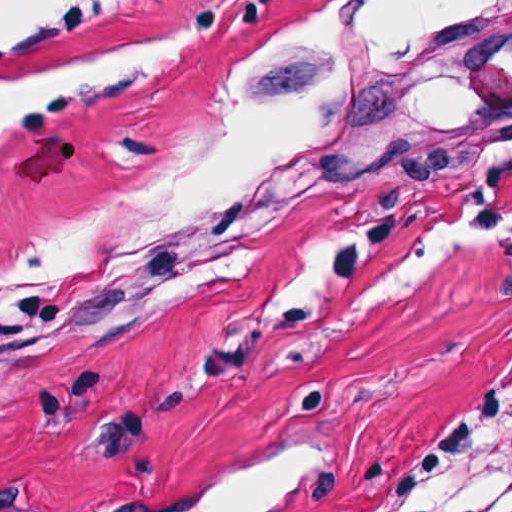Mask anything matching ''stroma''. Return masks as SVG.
I'll use <instances>...</instances> for the list:
<instances>
[{
  "instance_id": "1",
  "label": "stroma",
  "mask_w": 512,
  "mask_h": 512,
  "mask_svg": "<svg viewBox=\"0 0 512 512\" xmlns=\"http://www.w3.org/2000/svg\"><path fill=\"white\" fill-rule=\"evenodd\" d=\"M309 1L61 0L2 40L6 83L210 33L134 92L0 140V249L196 118ZM510 427L512 23L477 123L357 163L277 244L214 220L174 309L0 341V512H141L276 454L286 512H404Z\"/></svg>"
}]
</instances>
